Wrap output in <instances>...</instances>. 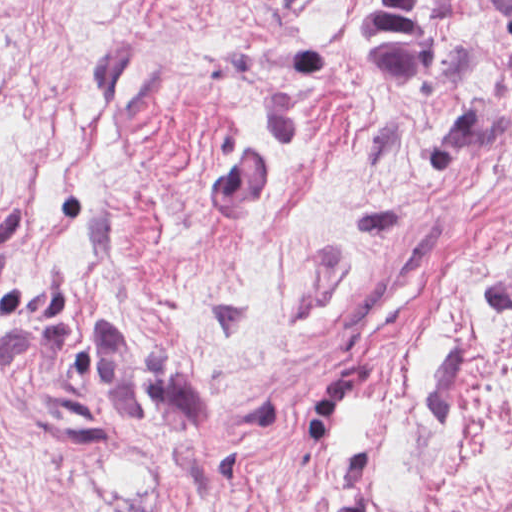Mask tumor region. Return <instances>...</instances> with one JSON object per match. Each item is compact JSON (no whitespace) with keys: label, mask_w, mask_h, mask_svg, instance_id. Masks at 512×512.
Returning a JSON list of instances; mask_svg holds the SVG:
<instances>
[{"label":"tumor region","mask_w":512,"mask_h":512,"mask_svg":"<svg viewBox=\"0 0 512 512\" xmlns=\"http://www.w3.org/2000/svg\"><path fill=\"white\" fill-rule=\"evenodd\" d=\"M512 14V1H502ZM442 1H353L348 30L380 95L399 96L423 60Z\"/></svg>","instance_id":"obj_1"}]
</instances>
